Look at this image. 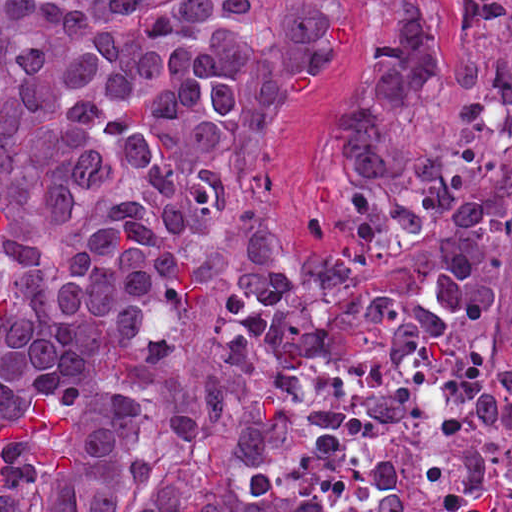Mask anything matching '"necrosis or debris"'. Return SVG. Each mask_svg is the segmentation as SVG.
<instances>
[{
    "label": "necrosis or debris",
    "instance_id": "1",
    "mask_svg": "<svg viewBox=\"0 0 512 512\" xmlns=\"http://www.w3.org/2000/svg\"><path fill=\"white\" fill-rule=\"evenodd\" d=\"M441 333L411 352L421 358L367 343L289 352L279 453L288 502L368 512L366 494L397 489L420 454L453 443L490 374V337L472 336L453 359L425 358Z\"/></svg>",
    "mask_w": 512,
    "mask_h": 512
}]
</instances>
